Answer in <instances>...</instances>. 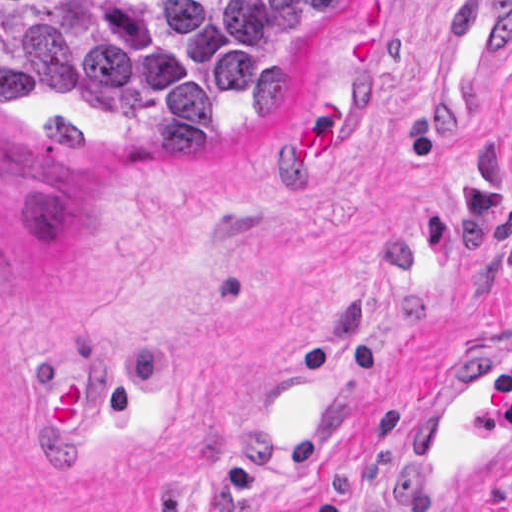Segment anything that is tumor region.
Wrapping results in <instances>:
<instances>
[{
    "label": "tumor region",
    "mask_w": 512,
    "mask_h": 512,
    "mask_svg": "<svg viewBox=\"0 0 512 512\" xmlns=\"http://www.w3.org/2000/svg\"><path fill=\"white\" fill-rule=\"evenodd\" d=\"M340 0H0V110L90 88L152 143L228 146L299 96Z\"/></svg>",
    "instance_id": "e687c5a6"
}]
</instances>
